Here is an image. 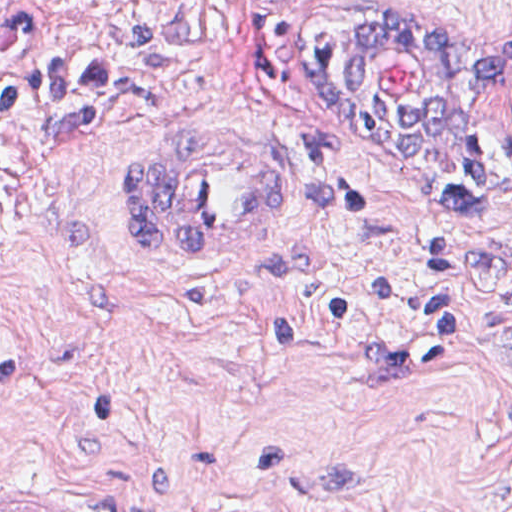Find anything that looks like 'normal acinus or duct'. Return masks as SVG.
<instances>
[{
	"mask_svg": "<svg viewBox=\"0 0 512 512\" xmlns=\"http://www.w3.org/2000/svg\"><path fill=\"white\" fill-rule=\"evenodd\" d=\"M402 7L411 12L358 9L340 18L326 36L323 71L381 148L443 158L512 91V23L445 34Z\"/></svg>",
	"mask_w": 512,
	"mask_h": 512,
	"instance_id": "30e58d81",
	"label": "normal acinus or duct"
}]
</instances>
